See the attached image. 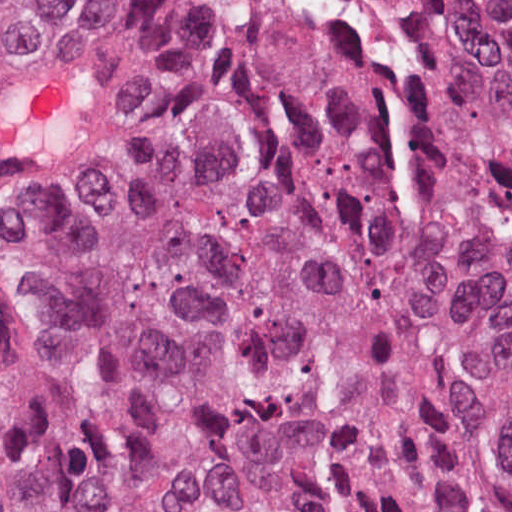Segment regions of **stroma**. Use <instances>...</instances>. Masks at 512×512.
Instances as JSON below:
<instances>
[{
    "instance_id": "35a3bbf8",
    "label": "stroma",
    "mask_w": 512,
    "mask_h": 512,
    "mask_svg": "<svg viewBox=\"0 0 512 512\" xmlns=\"http://www.w3.org/2000/svg\"><path fill=\"white\" fill-rule=\"evenodd\" d=\"M121 101L109 43L31 40L0 0V316H47L78 292L99 246Z\"/></svg>"
}]
</instances>
